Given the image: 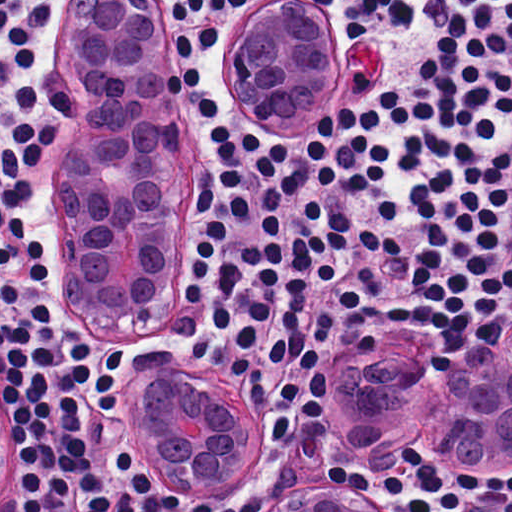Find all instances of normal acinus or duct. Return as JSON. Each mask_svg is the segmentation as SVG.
<instances>
[{"instance_id": "normal-acinus-or-duct-1", "label": "normal acinus or duct", "mask_w": 512, "mask_h": 512, "mask_svg": "<svg viewBox=\"0 0 512 512\" xmlns=\"http://www.w3.org/2000/svg\"><path fill=\"white\" fill-rule=\"evenodd\" d=\"M60 27L81 65L79 155L58 189L64 310L78 326L130 342L171 339L182 326L197 243V133L161 27L143 0H61ZM321 43L304 10L276 7L250 31L252 84L276 125L311 128ZM426 384L360 363L334 409V450L365 464L369 450L417 434L473 452L512 456V319L475 359L447 358ZM146 460L170 488H221L260 459L252 419L230 421L203 391L152 377L128 404ZM317 480L302 498L259 512H381L356 487Z\"/></svg>"}]
</instances>
